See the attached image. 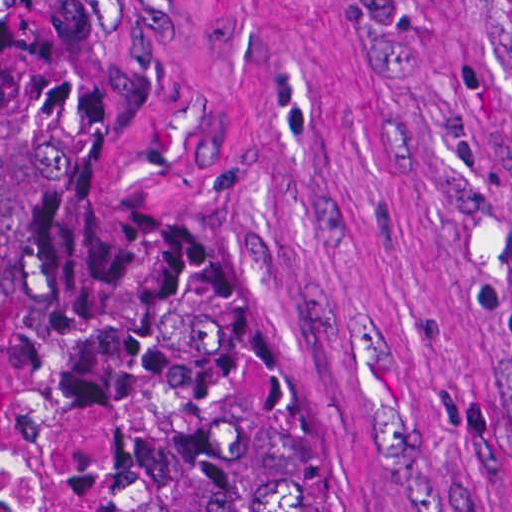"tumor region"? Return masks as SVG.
I'll use <instances>...</instances> for the list:
<instances>
[{"label":"tumor region","instance_id":"tumor-region-1","mask_svg":"<svg viewBox=\"0 0 512 512\" xmlns=\"http://www.w3.org/2000/svg\"><path fill=\"white\" fill-rule=\"evenodd\" d=\"M0 329L110 512H362L76 1H0Z\"/></svg>","mask_w":512,"mask_h":512}]
</instances>
